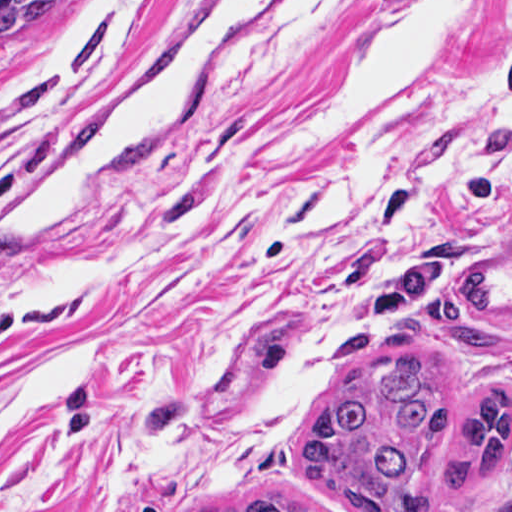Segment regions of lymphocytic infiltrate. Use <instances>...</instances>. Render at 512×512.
<instances>
[{
  "mask_svg": "<svg viewBox=\"0 0 512 512\" xmlns=\"http://www.w3.org/2000/svg\"><path fill=\"white\" fill-rule=\"evenodd\" d=\"M504 75L512 88V30L500 47ZM463 209L471 215H492L512 210V165L480 170L463 188Z\"/></svg>",
  "mask_w": 512,
  "mask_h": 512,
  "instance_id": "f902f5d3",
  "label": "lymphocytic infiltrate"
}]
</instances>
